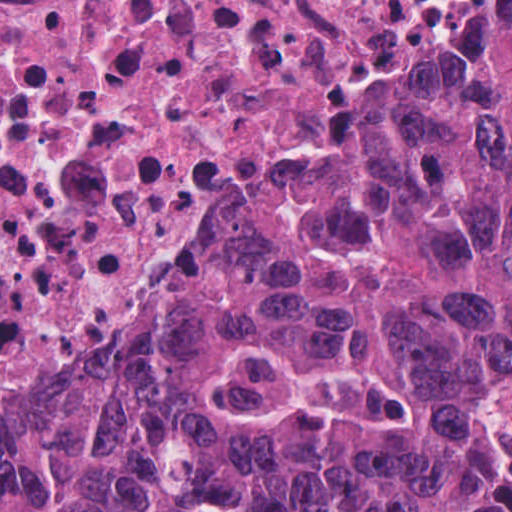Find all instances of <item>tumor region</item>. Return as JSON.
Listing matches in <instances>:
<instances>
[{
	"label": "tumor region",
	"mask_w": 512,
	"mask_h": 512,
	"mask_svg": "<svg viewBox=\"0 0 512 512\" xmlns=\"http://www.w3.org/2000/svg\"><path fill=\"white\" fill-rule=\"evenodd\" d=\"M511 387L512 16L0 419V512H512Z\"/></svg>",
	"instance_id": "e687c5a6"
}]
</instances>
